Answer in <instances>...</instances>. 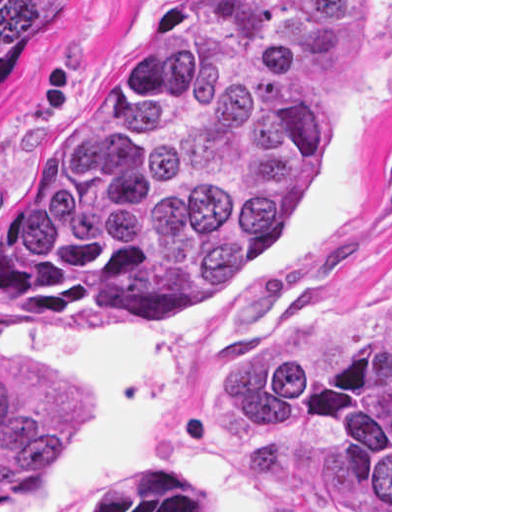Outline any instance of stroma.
<instances>
[{
  "label": "stroma",
  "instance_id": "1",
  "mask_svg": "<svg viewBox=\"0 0 512 512\" xmlns=\"http://www.w3.org/2000/svg\"><path fill=\"white\" fill-rule=\"evenodd\" d=\"M178 0H55L0 82V184L38 154L75 89ZM322 165L224 299L143 312H47L0 292V363L80 386L83 443L0 512H328L223 444L237 363L300 313L390 302L392 0H370V57L316 98ZM389 312L380 321L388 316Z\"/></svg>",
  "mask_w": 512,
  "mask_h": 512
}]
</instances>
